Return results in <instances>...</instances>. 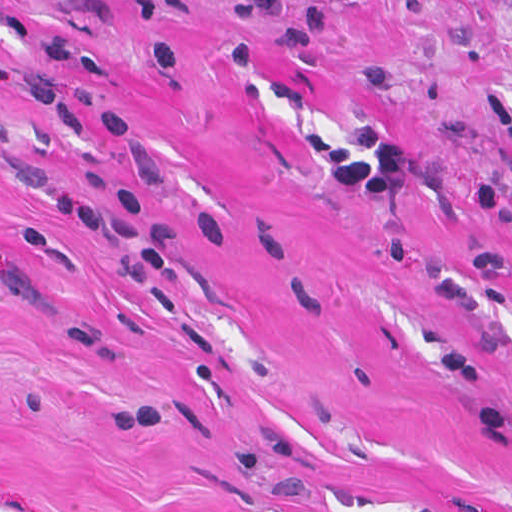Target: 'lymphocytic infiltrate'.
I'll return each instance as SVG.
<instances>
[{
  "instance_id": "f902f5d3",
  "label": "lymphocytic infiltrate",
  "mask_w": 512,
  "mask_h": 512,
  "mask_svg": "<svg viewBox=\"0 0 512 512\" xmlns=\"http://www.w3.org/2000/svg\"><path fill=\"white\" fill-rule=\"evenodd\" d=\"M353 140L370 157L361 160L343 145L329 144L322 136L310 135L323 168L333 177L372 197H396L406 188L411 172V156L377 123H360ZM473 209L490 220L502 223L512 238V201L494 189L480 188L469 195Z\"/></svg>"
}]
</instances>
